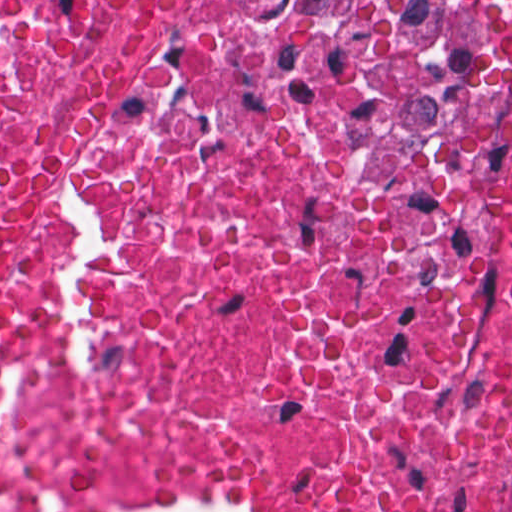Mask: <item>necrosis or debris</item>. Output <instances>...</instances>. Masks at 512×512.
<instances>
[{
	"mask_svg": "<svg viewBox=\"0 0 512 512\" xmlns=\"http://www.w3.org/2000/svg\"><path fill=\"white\" fill-rule=\"evenodd\" d=\"M0 512H512V0H0Z\"/></svg>",
	"mask_w": 512,
	"mask_h": 512,
	"instance_id": "1",
	"label": "necrosis or debris"
}]
</instances>
